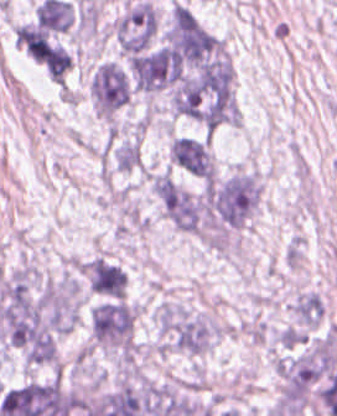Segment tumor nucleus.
Instances as JSON below:
<instances>
[{
    "label": "tumor nucleus",
    "mask_w": 337,
    "mask_h": 416,
    "mask_svg": "<svg viewBox=\"0 0 337 416\" xmlns=\"http://www.w3.org/2000/svg\"><path fill=\"white\" fill-rule=\"evenodd\" d=\"M261 198V185L251 171H237L208 184L206 210L219 228L241 226L256 211Z\"/></svg>",
    "instance_id": "1"
},
{
    "label": "tumor nucleus",
    "mask_w": 337,
    "mask_h": 416,
    "mask_svg": "<svg viewBox=\"0 0 337 416\" xmlns=\"http://www.w3.org/2000/svg\"><path fill=\"white\" fill-rule=\"evenodd\" d=\"M156 319L167 345L175 350L201 353L217 335V324L174 304H161Z\"/></svg>",
    "instance_id": "2"
},
{
    "label": "tumor nucleus",
    "mask_w": 337,
    "mask_h": 416,
    "mask_svg": "<svg viewBox=\"0 0 337 416\" xmlns=\"http://www.w3.org/2000/svg\"><path fill=\"white\" fill-rule=\"evenodd\" d=\"M319 365L315 351L278 360V405L297 416L303 409L317 379Z\"/></svg>",
    "instance_id": "3"
},
{
    "label": "tumor nucleus",
    "mask_w": 337,
    "mask_h": 416,
    "mask_svg": "<svg viewBox=\"0 0 337 416\" xmlns=\"http://www.w3.org/2000/svg\"><path fill=\"white\" fill-rule=\"evenodd\" d=\"M87 316L94 341L132 350L134 310L127 302L114 297L104 299L91 305Z\"/></svg>",
    "instance_id": "4"
},
{
    "label": "tumor nucleus",
    "mask_w": 337,
    "mask_h": 416,
    "mask_svg": "<svg viewBox=\"0 0 337 416\" xmlns=\"http://www.w3.org/2000/svg\"><path fill=\"white\" fill-rule=\"evenodd\" d=\"M89 90L97 114L112 115L128 102L131 80L123 66L104 61L97 66Z\"/></svg>",
    "instance_id": "5"
},
{
    "label": "tumor nucleus",
    "mask_w": 337,
    "mask_h": 416,
    "mask_svg": "<svg viewBox=\"0 0 337 416\" xmlns=\"http://www.w3.org/2000/svg\"><path fill=\"white\" fill-rule=\"evenodd\" d=\"M156 31L155 10L144 0L134 2L116 21L119 47L131 56L148 48Z\"/></svg>",
    "instance_id": "6"
},
{
    "label": "tumor nucleus",
    "mask_w": 337,
    "mask_h": 416,
    "mask_svg": "<svg viewBox=\"0 0 337 416\" xmlns=\"http://www.w3.org/2000/svg\"><path fill=\"white\" fill-rule=\"evenodd\" d=\"M157 196L170 222L184 232H201V204L194 195L174 180L159 177Z\"/></svg>",
    "instance_id": "7"
},
{
    "label": "tumor nucleus",
    "mask_w": 337,
    "mask_h": 416,
    "mask_svg": "<svg viewBox=\"0 0 337 416\" xmlns=\"http://www.w3.org/2000/svg\"><path fill=\"white\" fill-rule=\"evenodd\" d=\"M169 149L174 165L193 176L213 179L214 171L207 140L175 137Z\"/></svg>",
    "instance_id": "8"
},
{
    "label": "tumor nucleus",
    "mask_w": 337,
    "mask_h": 416,
    "mask_svg": "<svg viewBox=\"0 0 337 416\" xmlns=\"http://www.w3.org/2000/svg\"><path fill=\"white\" fill-rule=\"evenodd\" d=\"M44 65L50 78L64 84L71 68L70 52L64 45L50 41Z\"/></svg>",
    "instance_id": "9"
},
{
    "label": "tumor nucleus",
    "mask_w": 337,
    "mask_h": 416,
    "mask_svg": "<svg viewBox=\"0 0 337 416\" xmlns=\"http://www.w3.org/2000/svg\"><path fill=\"white\" fill-rule=\"evenodd\" d=\"M323 301L319 295L312 293L301 294L293 304V311L298 321L317 325L322 313Z\"/></svg>",
    "instance_id": "10"
}]
</instances>
